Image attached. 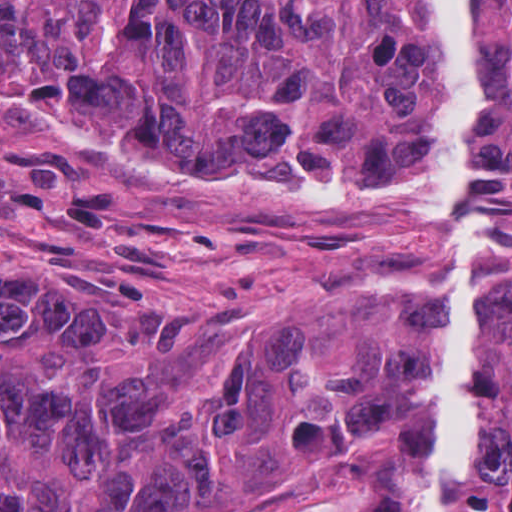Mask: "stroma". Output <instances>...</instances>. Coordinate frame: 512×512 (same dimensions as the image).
<instances>
[{
    "label": "stroma",
    "instance_id": "stroma-1",
    "mask_svg": "<svg viewBox=\"0 0 512 512\" xmlns=\"http://www.w3.org/2000/svg\"><path fill=\"white\" fill-rule=\"evenodd\" d=\"M477 217L480 292H512V225ZM433 224L197 169L80 163L0 127V284L70 295L110 343L190 318L246 331L285 312L323 368L385 334L422 359L425 324L401 321L427 303ZM481 366L512 370V338L481 334ZM411 463L407 428L291 466L244 440L218 493L185 512H386Z\"/></svg>",
    "mask_w": 512,
    "mask_h": 512
}]
</instances>
